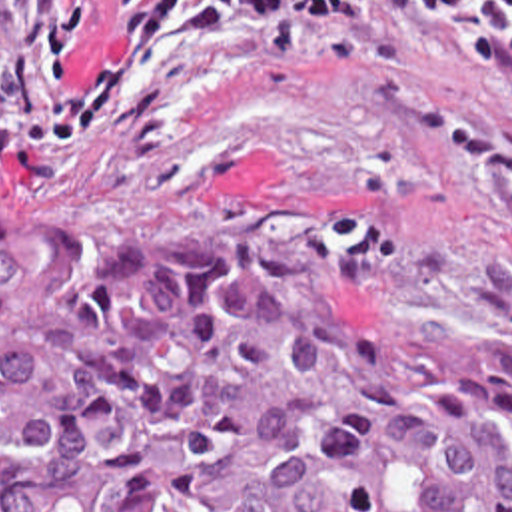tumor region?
Instances as JSON below:
<instances>
[{"instance_id":"e687c5a6","label":"tumor region","mask_w":512,"mask_h":512,"mask_svg":"<svg viewBox=\"0 0 512 512\" xmlns=\"http://www.w3.org/2000/svg\"><path fill=\"white\" fill-rule=\"evenodd\" d=\"M512 512V351L0 200V512Z\"/></svg>"}]
</instances>
